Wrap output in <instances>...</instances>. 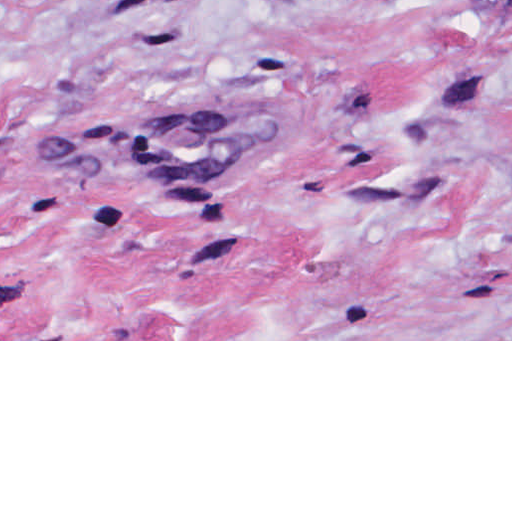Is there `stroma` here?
Wrapping results in <instances>:
<instances>
[{
	"label": "stroma",
	"mask_w": 512,
	"mask_h": 512,
	"mask_svg": "<svg viewBox=\"0 0 512 512\" xmlns=\"http://www.w3.org/2000/svg\"><path fill=\"white\" fill-rule=\"evenodd\" d=\"M0 341H512V0H0Z\"/></svg>",
	"instance_id": "35a3bbf8"
}]
</instances>
